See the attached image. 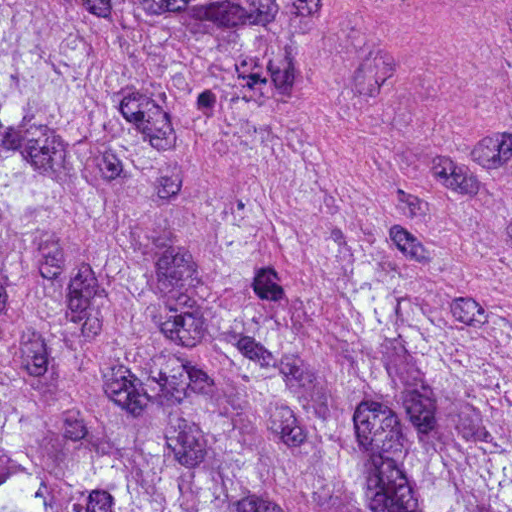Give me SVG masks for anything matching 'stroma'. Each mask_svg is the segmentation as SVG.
I'll return each instance as SVG.
<instances>
[{
	"mask_svg": "<svg viewBox=\"0 0 512 512\" xmlns=\"http://www.w3.org/2000/svg\"><path fill=\"white\" fill-rule=\"evenodd\" d=\"M229 163L512 371V0H331Z\"/></svg>",
	"mask_w": 512,
	"mask_h": 512,
	"instance_id": "stroma-1",
	"label": "stroma"
}]
</instances>
